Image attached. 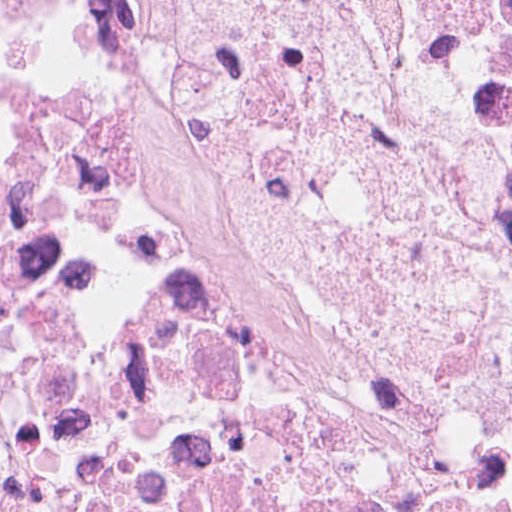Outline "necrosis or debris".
Wrapping results in <instances>:
<instances>
[{
	"instance_id": "necrosis-or-debris-1",
	"label": "necrosis or debris",
	"mask_w": 512,
	"mask_h": 512,
	"mask_svg": "<svg viewBox=\"0 0 512 512\" xmlns=\"http://www.w3.org/2000/svg\"><path fill=\"white\" fill-rule=\"evenodd\" d=\"M323 0H104L220 146L301 145ZM360 202L512 291V0H339ZM0 512H512V437L246 247L37 0H0Z\"/></svg>"
}]
</instances>
